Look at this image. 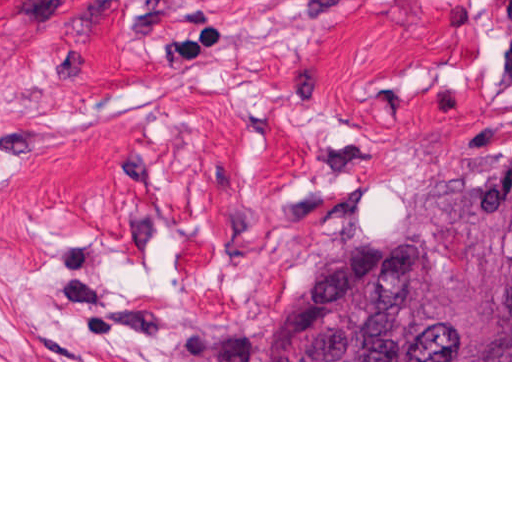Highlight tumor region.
I'll use <instances>...</instances> for the list:
<instances>
[{
  "instance_id": "obj_1",
  "label": "tumor region",
  "mask_w": 512,
  "mask_h": 512,
  "mask_svg": "<svg viewBox=\"0 0 512 512\" xmlns=\"http://www.w3.org/2000/svg\"><path fill=\"white\" fill-rule=\"evenodd\" d=\"M258 360H512V160L326 269Z\"/></svg>"
}]
</instances>
